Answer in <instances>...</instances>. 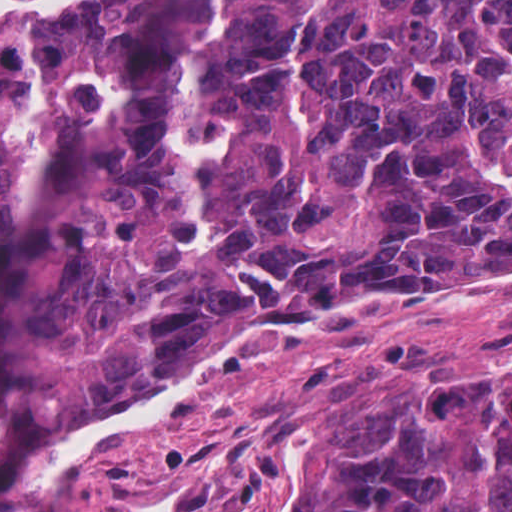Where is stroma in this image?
Wrapping results in <instances>:
<instances>
[{"label":"stroma","instance_id":"1","mask_svg":"<svg viewBox=\"0 0 512 512\" xmlns=\"http://www.w3.org/2000/svg\"><path fill=\"white\" fill-rule=\"evenodd\" d=\"M128 1L0 0V51ZM510 269L333 302L226 391L190 397L178 412L82 457L57 483L26 487L24 474L48 448L142 391L45 402L0 512H307L292 505L276 474L293 434L326 417L467 391L512 371V283L449 289Z\"/></svg>","mask_w":512,"mask_h":512}]
</instances>
